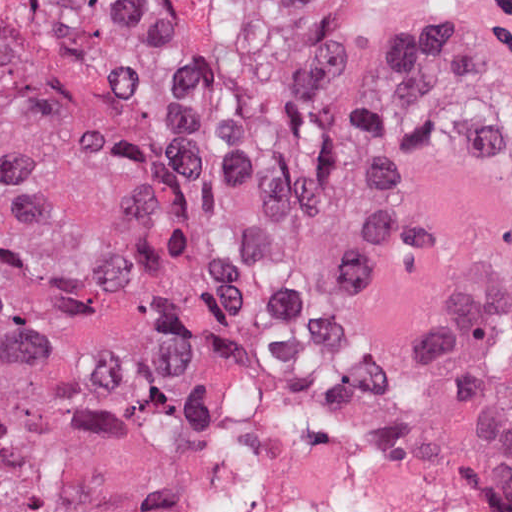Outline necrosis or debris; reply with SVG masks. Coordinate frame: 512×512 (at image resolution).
I'll return each mask as SVG.
<instances>
[{"mask_svg":"<svg viewBox=\"0 0 512 512\" xmlns=\"http://www.w3.org/2000/svg\"><path fill=\"white\" fill-rule=\"evenodd\" d=\"M279 435L243 512H512L436 427L364 374L275 356Z\"/></svg>","mask_w":512,"mask_h":512,"instance_id":"obj_1","label":"necrosis or debris"}]
</instances>
